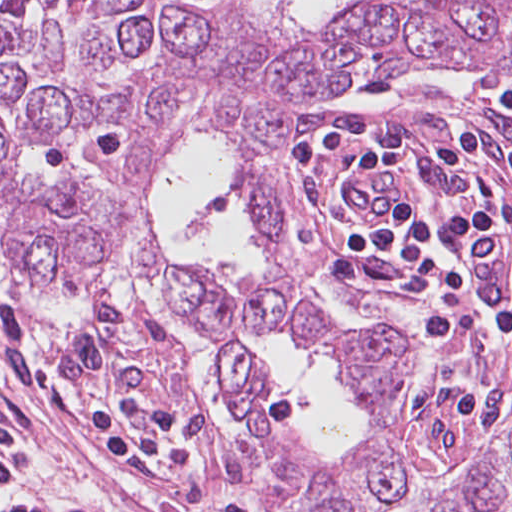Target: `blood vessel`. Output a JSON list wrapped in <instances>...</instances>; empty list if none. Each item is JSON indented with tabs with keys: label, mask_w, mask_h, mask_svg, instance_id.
I'll list each match as a JSON object with an SVG mask.
<instances>
[{
	"label": "blood vessel",
	"mask_w": 512,
	"mask_h": 512,
	"mask_svg": "<svg viewBox=\"0 0 512 512\" xmlns=\"http://www.w3.org/2000/svg\"><path fill=\"white\" fill-rule=\"evenodd\" d=\"M366 166L355 171H352L342 177L338 184L337 192L340 198L341 205L344 210L343 193L344 186L356 182L364 177L380 180V179H393L400 176V168L396 164H384L378 166ZM402 210V199L392 201L389 209L383 219L377 222H363L357 221L346 217L358 229L363 231H384L386 230L400 215ZM345 212V210H344Z\"/></svg>",
	"instance_id": "8fb6f2fc"
}]
</instances>
